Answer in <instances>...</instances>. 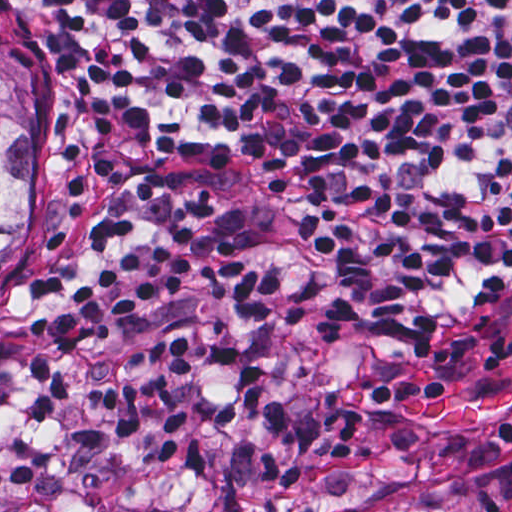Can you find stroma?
Listing matches in <instances>:
<instances>
[{"instance_id": "stroma-1", "label": "stroma", "mask_w": 512, "mask_h": 512, "mask_svg": "<svg viewBox=\"0 0 512 512\" xmlns=\"http://www.w3.org/2000/svg\"><path fill=\"white\" fill-rule=\"evenodd\" d=\"M0 44L34 85V225L0 280V512H512V280L442 328L391 339L373 328L347 263L276 190L167 152L125 121L31 0H0ZM152 169L184 193L210 187V223L275 275L284 307L252 326L207 301L201 280L93 337L75 365L122 383L129 353L155 336L223 338L267 367L311 451L221 428L217 404L237 385L208 361L170 378L189 426L168 460L126 440L96 391L42 428L29 420L27 330L112 258L92 223L124 213L135 242L178 221L169 200L133 194Z\"/></svg>"}]
</instances>
